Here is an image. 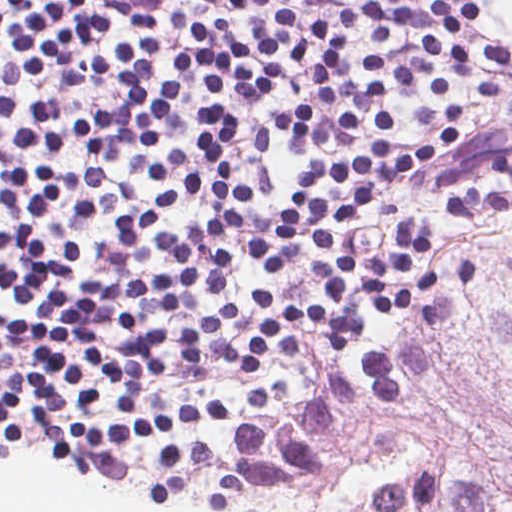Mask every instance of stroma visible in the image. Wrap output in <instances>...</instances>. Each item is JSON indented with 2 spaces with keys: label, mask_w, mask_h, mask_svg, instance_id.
Listing matches in <instances>:
<instances>
[{
  "label": "stroma",
  "mask_w": 512,
  "mask_h": 512,
  "mask_svg": "<svg viewBox=\"0 0 512 512\" xmlns=\"http://www.w3.org/2000/svg\"><path fill=\"white\" fill-rule=\"evenodd\" d=\"M481 19L467 35L506 47L512 40L488 27L495 0H473ZM108 24L104 43L126 32L133 13L156 15L158 68L166 76L170 53L187 46L175 13L187 22L207 19L201 0H99ZM334 0H305L311 20L328 16ZM349 68L332 84L304 81L299 60H287L284 87L268 99H224L244 119V145L234 150L232 171L251 178L259 128L302 102L317 111L311 143L300 145L289 130L278 134L270 167L279 188L290 192L300 170L332 158L346 147L336 128L342 108L359 122L353 141H371L370 102L391 106L396 150L417 148L425 130L416 113L423 106L456 104L464 112V147L414 180L385 195L371 214L347 231L350 249L372 255L381 249L390 225L400 217L428 223L434 244L424 263L431 269L456 263L477 280L433 284L423 305L407 312L361 305L363 322L349 353L327 346L315 327L304 330L301 351L269 361L262 380L292 394L271 415L329 433L481 484L512 493V206L478 216H449V195L469 186L512 193V180L493 175V154L512 139V62L485 66L457 79L444 97L433 95L425 74L418 88L373 100L362 87V29L351 38ZM96 78V77H95ZM24 105L50 100L72 119H90L118 108L122 96L110 83L89 76L74 94H60L43 70L23 94ZM210 97L198 85L175 89L155 140L140 148L150 166L193 141ZM11 117L0 116V153L12 152ZM0 305L25 312L10 293ZM245 376L233 371L208 379H161L245 407Z\"/></svg>",
  "instance_id": "1"
}]
</instances>
